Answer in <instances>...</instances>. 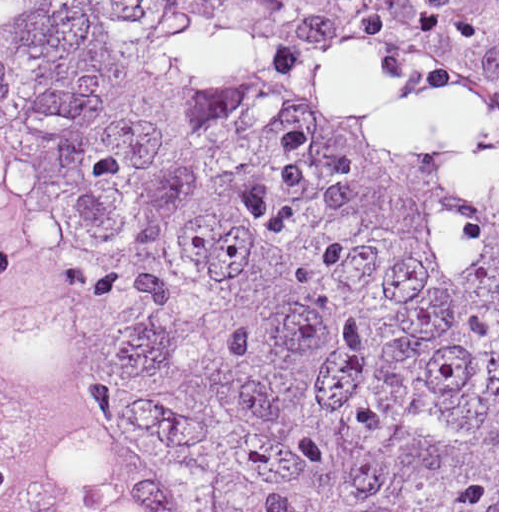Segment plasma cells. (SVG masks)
<instances>
[{"instance_id":"obj_1","label":"plasma cells","mask_w":512,"mask_h":512,"mask_svg":"<svg viewBox=\"0 0 512 512\" xmlns=\"http://www.w3.org/2000/svg\"><path fill=\"white\" fill-rule=\"evenodd\" d=\"M335 24L433 57L498 128V0H301Z\"/></svg>"}]
</instances>
